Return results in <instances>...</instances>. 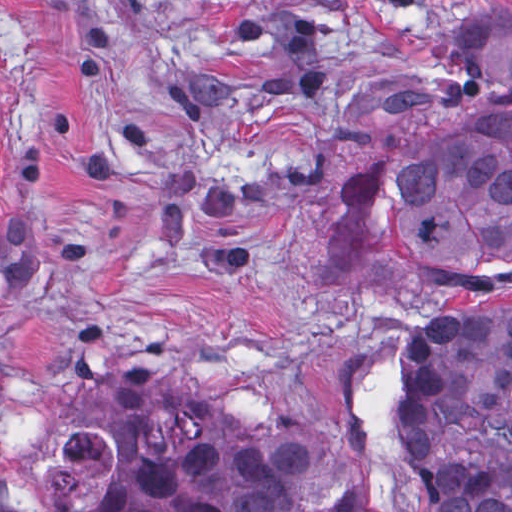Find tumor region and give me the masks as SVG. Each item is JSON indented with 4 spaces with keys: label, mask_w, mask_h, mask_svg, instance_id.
<instances>
[{
    "label": "tumor region",
    "mask_w": 512,
    "mask_h": 512,
    "mask_svg": "<svg viewBox=\"0 0 512 512\" xmlns=\"http://www.w3.org/2000/svg\"><path fill=\"white\" fill-rule=\"evenodd\" d=\"M443 53L484 73L497 98L456 126L394 135L337 189L349 216L382 219L397 264L512 246V9L449 23ZM5 163L0 105V179ZM379 364L298 415L185 385L155 395L146 408L168 418L178 450L95 512H396L377 462ZM399 373L398 437L430 512H512V289L420 324Z\"/></svg>",
    "instance_id": "tumor-region-1"
}]
</instances>
